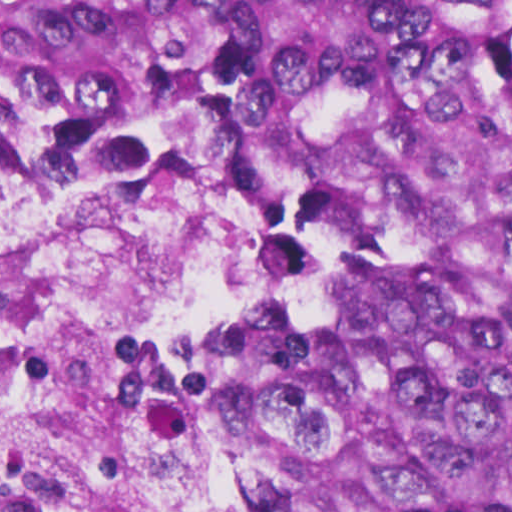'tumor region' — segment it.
<instances>
[{
  "mask_svg": "<svg viewBox=\"0 0 512 512\" xmlns=\"http://www.w3.org/2000/svg\"><path fill=\"white\" fill-rule=\"evenodd\" d=\"M278 161L268 319L189 404L232 512H512V0H0V157Z\"/></svg>",
  "mask_w": 512,
  "mask_h": 512,
  "instance_id": "obj_1",
  "label": "tumor region"
}]
</instances>
